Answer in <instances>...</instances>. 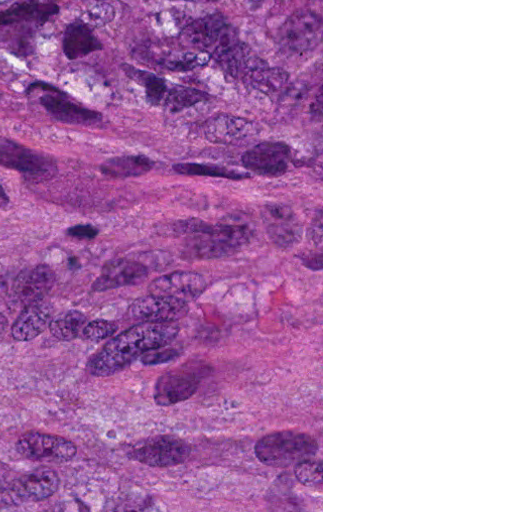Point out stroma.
I'll list each match as a JSON object with an SVG mask.
<instances>
[{
	"label": "stroma",
	"instance_id": "stroma-1",
	"mask_svg": "<svg viewBox=\"0 0 512 512\" xmlns=\"http://www.w3.org/2000/svg\"><path fill=\"white\" fill-rule=\"evenodd\" d=\"M161 512H323V0H161Z\"/></svg>",
	"mask_w": 512,
	"mask_h": 512
}]
</instances>
